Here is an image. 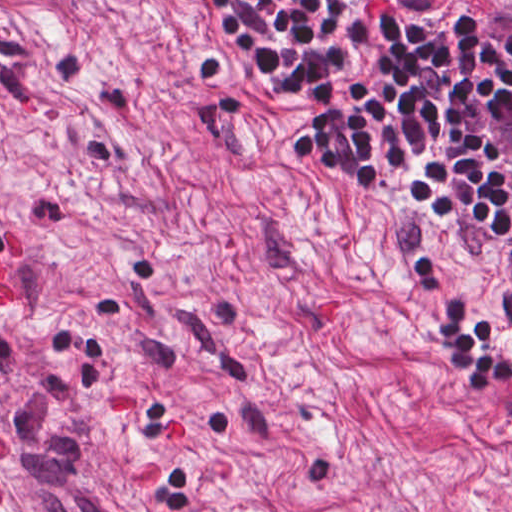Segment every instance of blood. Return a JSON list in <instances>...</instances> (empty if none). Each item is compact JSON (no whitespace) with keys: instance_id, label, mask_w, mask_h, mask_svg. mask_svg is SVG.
I'll return each mask as SVG.
<instances>
[{"instance_id":"obj_1","label":"blood","mask_w":512,"mask_h":512,"mask_svg":"<svg viewBox=\"0 0 512 512\" xmlns=\"http://www.w3.org/2000/svg\"><path fill=\"white\" fill-rule=\"evenodd\" d=\"M8 246L12 254L21 258L18 238L8 236ZM0 311H13L16 293L6 288V275L0 261ZM185 435V418L180 412L171 414L165 420V432ZM126 486H148L160 478V464L153 451L142 452L126 463L124 473ZM201 512V510H200Z\"/></svg>"}]
</instances>
